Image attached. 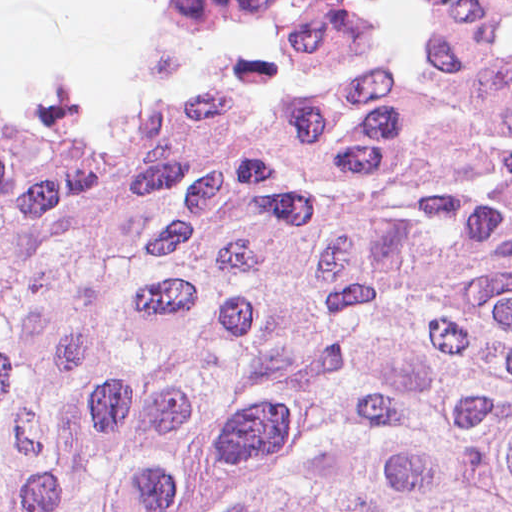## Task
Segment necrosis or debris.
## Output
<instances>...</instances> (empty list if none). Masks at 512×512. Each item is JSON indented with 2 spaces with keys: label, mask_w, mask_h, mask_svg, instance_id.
Listing matches in <instances>:
<instances>
[{
  "label": "necrosis or debris",
  "mask_w": 512,
  "mask_h": 512,
  "mask_svg": "<svg viewBox=\"0 0 512 512\" xmlns=\"http://www.w3.org/2000/svg\"><path fill=\"white\" fill-rule=\"evenodd\" d=\"M173 13L223 19L234 27L271 31L273 50L286 53H362L390 43L377 21L341 0H155ZM502 0H433V29Z\"/></svg>",
  "instance_id": "necrosis-or-debris-1"
}]
</instances>
